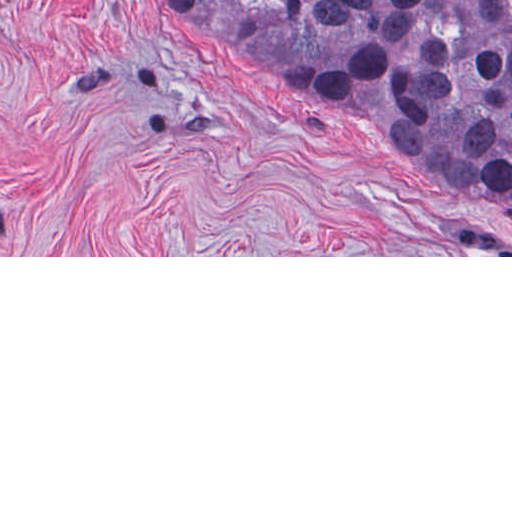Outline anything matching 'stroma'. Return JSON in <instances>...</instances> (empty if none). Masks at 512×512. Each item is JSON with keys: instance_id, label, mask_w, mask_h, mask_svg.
<instances>
[{"instance_id": "obj_1", "label": "stroma", "mask_w": 512, "mask_h": 512, "mask_svg": "<svg viewBox=\"0 0 512 512\" xmlns=\"http://www.w3.org/2000/svg\"><path fill=\"white\" fill-rule=\"evenodd\" d=\"M0 257H512V205L161 0H0Z\"/></svg>"}]
</instances>
